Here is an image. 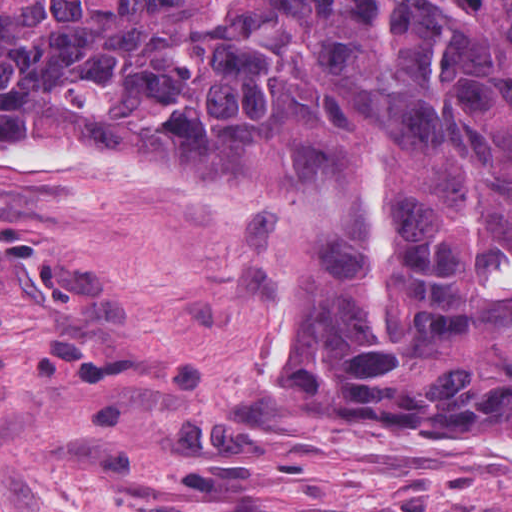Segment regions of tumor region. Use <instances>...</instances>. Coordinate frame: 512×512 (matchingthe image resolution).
I'll return each instance as SVG.
<instances>
[{"label":"tumor region","instance_id":"obj_1","mask_svg":"<svg viewBox=\"0 0 512 512\" xmlns=\"http://www.w3.org/2000/svg\"><path fill=\"white\" fill-rule=\"evenodd\" d=\"M6 135L278 194L254 329L371 424L512 431V0H0Z\"/></svg>","mask_w":512,"mask_h":512}]
</instances>
